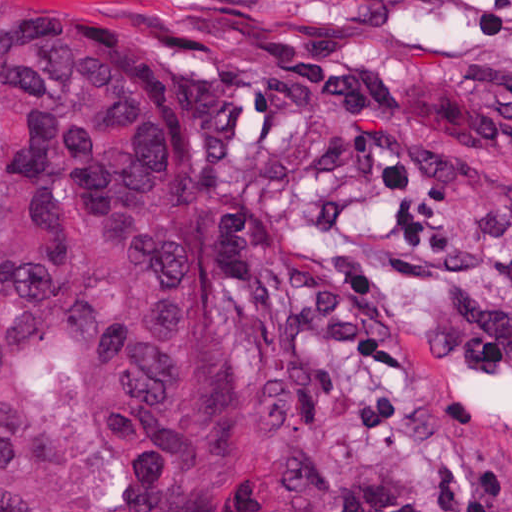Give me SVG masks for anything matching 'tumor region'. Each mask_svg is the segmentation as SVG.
<instances>
[{"mask_svg": "<svg viewBox=\"0 0 512 512\" xmlns=\"http://www.w3.org/2000/svg\"><path fill=\"white\" fill-rule=\"evenodd\" d=\"M264 396L182 125L0 0V512H256Z\"/></svg>", "mask_w": 512, "mask_h": 512, "instance_id": "e687c5a6", "label": "tumor region"}]
</instances>
